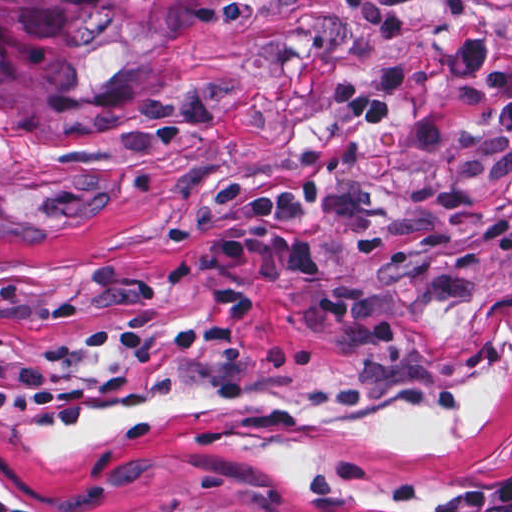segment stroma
<instances>
[{"label":"stroma","instance_id":"stroma-1","mask_svg":"<svg viewBox=\"0 0 512 512\" xmlns=\"http://www.w3.org/2000/svg\"><path fill=\"white\" fill-rule=\"evenodd\" d=\"M512 0H299L213 24L107 130L1 114L0 512L209 493L450 512L512 477V136L452 63ZM395 53L392 126L336 85ZM320 184L322 277L249 236Z\"/></svg>","mask_w":512,"mask_h":512}]
</instances>
